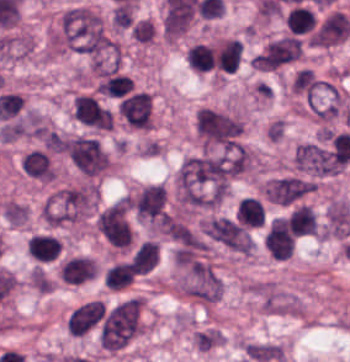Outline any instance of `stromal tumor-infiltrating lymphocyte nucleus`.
I'll return each instance as SVG.
<instances>
[{
    "label": "stromal tumor-infiltrating lymphocyte nucleus",
    "mask_w": 350,
    "mask_h": 362,
    "mask_svg": "<svg viewBox=\"0 0 350 362\" xmlns=\"http://www.w3.org/2000/svg\"><path fill=\"white\" fill-rule=\"evenodd\" d=\"M103 280L110 289H119L132 281V265L115 261L103 271Z\"/></svg>",
    "instance_id": "6"
},
{
    "label": "stromal tumor-infiltrating lymphocyte nucleus",
    "mask_w": 350,
    "mask_h": 362,
    "mask_svg": "<svg viewBox=\"0 0 350 362\" xmlns=\"http://www.w3.org/2000/svg\"><path fill=\"white\" fill-rule=\"evenodd\" d=\"M213 49L201 42H193L185 53V62L193 71H201L212 64Z\"/></svg>",
    "instance_id": "7"
},
{
    "label": "stromal tumor-infiltrating lymphocyte nucleus",
    "mask_w": 350,
    "mask_h": 362,
    "mask_svg": "<svg viewBox=\"0 0 350 362\" xmlns=\"http://www.w3.org/2000/svg\"><path fill=\"white\" fill-rule=\"evenodd\" d=\"M25 251L32 260L50 263L59 258L60 240L52 234L37 232L27 237Z\"/></svg>",
    "instance_id": "2"
},
{
    "label": "stromal tumor-infiltrating lymphocyte nucleus",
    "mask_w": 350,
    "mask_h": 362,
    "mask_svg": "<svg viewBox=\"0 0 350 362\" xmlns=\"http://www.w3.org/2000/svg\"><path fill=\"white\" fill-rule=\"evenodd\" d=\"M263 215V208L259 199L250 196H243L239 199L235 220L245 226H257Z\"/></svg>",
    "instance_id": "3"
},
{
    "label": "stromal tumor-infiltrating lymphocyte nucleus",
    "mask_w": 350,
    "mask_h": 362,
    "mask_svg": "<svg viewBox=\"0 0 350 362\" xmlns=\"http://www.w3.org/2000/svg\"><path fill=\"white\" fill-rule=\"evenodd\" d=\"M157 254V243L151 239H144L135 249L129 262L136 273H144L154 265Z\"/></svg>",
    "instance_id": "4"
},
{
    "label": "stromal tumor-infiltrating lymphocyte nucleus",
    "mask_w": 350,
    "mask_h": 362,
    "mask_svg": "<svg viewBox=\"0 0 350 362\" xmlns=\"http://www.w3.org/2000/svg\"><path fill=\"white\" fill-rule=\"evenodd\" d=\"M117 110L129 127L149 129L150 95L146 92H133L118 101Z\"/></svg>",
    "instance_id": "1"
},
{
    "label": "stromal tumor-infiltrating lymphocyte nucleus",
    "mask_w": 350,
    "mask_h": 362,
    "mask_svg": "<svg viewBox=\"0 0 350 362\" xmlns=\"http://www.w3.org/2000/svg\"><path fill=\"white\" fill-rule=\"evenodd\" d=\"M132 82L130 78L112 70L101 76L97 92L110 96H122L130 90Z\"/></svg>",
    "instance_id": "5"
}]
</instances>
